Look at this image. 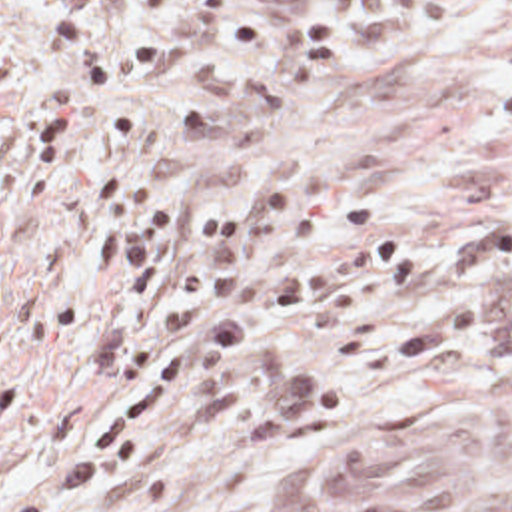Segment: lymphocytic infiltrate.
<instances>
[{
    "mask_svg": "<svg viewBox=\"0 0 512 512\" xmlns=\"http://www.w3.org/2000/svg\"><path fill=\"white\" fill-rule=\"evenodd\" d=\"M13 1L0 0V19ZM109 1H73L41 23L67 89H119L195 59L229 31L237 3L139 0L157 33L129 39L103 25ZM59 171L77 173L79 197L99 207L91 275L117 281L89 339L91 376L109 396L73 452L0 512H81L115 488L151 422L181 398L219 394L257 446L333 418L343 396L327 370L257 341L291 315L317 331L361 327L422 283V257L388 235L281 263L365 227L361 203L311 201L293 217L291 197L273 183L245 211L163 203L81 147V103L67 91L51 93L11 147V183L23 197H39ZM279 237L267 267L247 269Z\"/></svg>",
    "mask_w": 512,
    "mask_h": 512,
    "instance_id": "lymphocytic-infiltrate-1",
    "label": "lymphocytic infiltrate"
}]
</instances>
